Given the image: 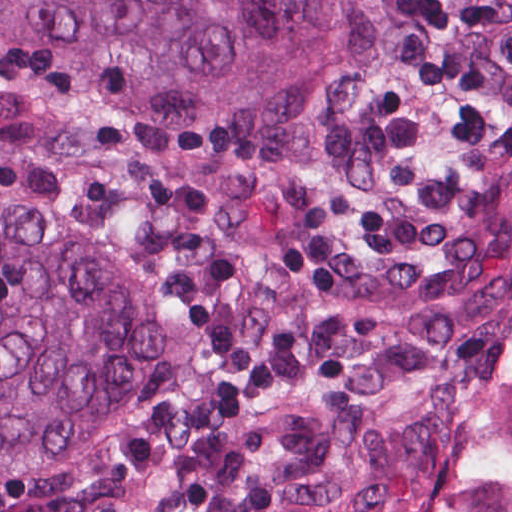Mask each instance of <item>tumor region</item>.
Listing matches in <instances>:
<instances>
[{
    "label": "tumor region",
    "instance_id": "obj_1",
    "mask_svg": "<svg viewBox=\"0 0 512 512\" xmlns=\"http://www.w3.org/2000/svg\"><path fill=\"white\" fill-rule=\"evenodd\" d=\"M512 337V0H0V512H373Z\"/></svg>",
    "mask_w": 512,
    "mask_h": 512
}]
</instances>
